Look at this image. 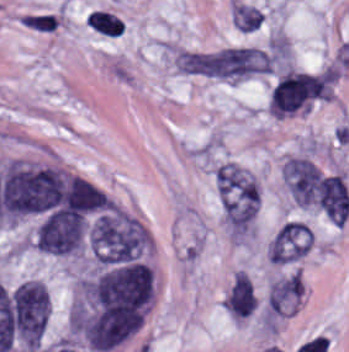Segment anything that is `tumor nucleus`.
Here are the masks:
<instances>
[{
  "label": "tumor nucleus",
  "instance_id": "1",
  "mask_svg": "<svg viewBox=\"0 0 349 352\" xmlns=\"http://www.w3.org/2000/svg\"><path fill=\"white\" fill-rule=\"evenodd\" d=\"M86 236L97 266L141 260L151 246V238L141 223L113 207H106L89 222Z\"/></svg>",
  "mask_w": 349,
  "mask_h": 352
},
{
  "label": "tumor nucleus",
  "instance_id": "2",
  "mask_svg": "<svg viewBox=\"0 0 349 352\" xmlns=\"http://www.w3.org/2000/svg\"><path fill=\"white\" fill-rule=\"evenodd\" d=\"M88 218L79 211H53L39 224L34 242L36 249L51 256H70L84 249Z\"/></svg>",
  "mask_w": 349,
  "mask_h": 352
}]
</instances>
